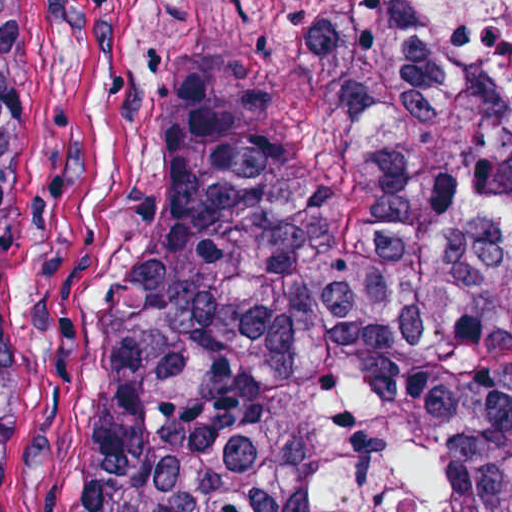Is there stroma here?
Segmentation results:
<instances>
[{
    "label": "stroma",
    "instance_id": "1",
    "mask_svg": "<svg viewBox=\"0 0 512 512\" xmlns=\"http://www.w3.org/2000/svg\"><path fill=\"white\" fill-rule=\"evenodd\" d=\"M384 2L460 98H512L433 53ZM0 52L27 239L3 512H71L88 321L127 250L162 78L177 63L212 66L267 113L323 78L287 0H0Z\"/></svg>",
    "mask_w": 512,
    "mask_h": 512
}]
</instances>
